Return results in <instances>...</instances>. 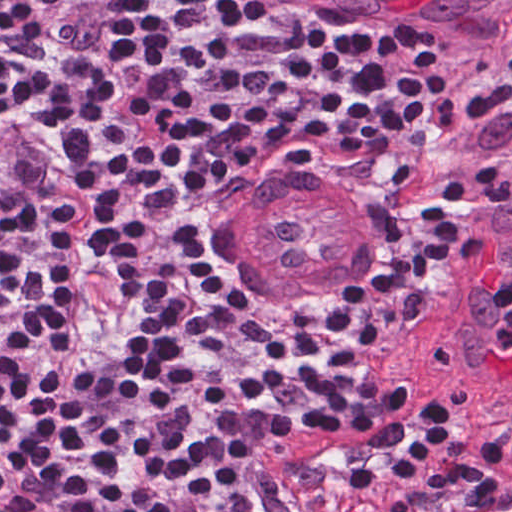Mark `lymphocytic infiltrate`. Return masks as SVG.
<instances>
[{
    "label": "lymphocytic infiltrate",
    "mask_w": 512,
    "mask_h": 512,
    "mask_svg": "<svg viewBox=\"0 0 512 512\" xmlns=\"http://www.w3.org/2000/svg\"><path fill=\"white\" fill-rule=\"evenodd\" d=\"M328 0H0V512H472L512 396L363 358L412 286L235 318L183 252L257 156L394 197L460 97ZM512 173V70L473 118Z\"/></svg>",
    "instance_id": "f902f5d3"
}]
</instances>
